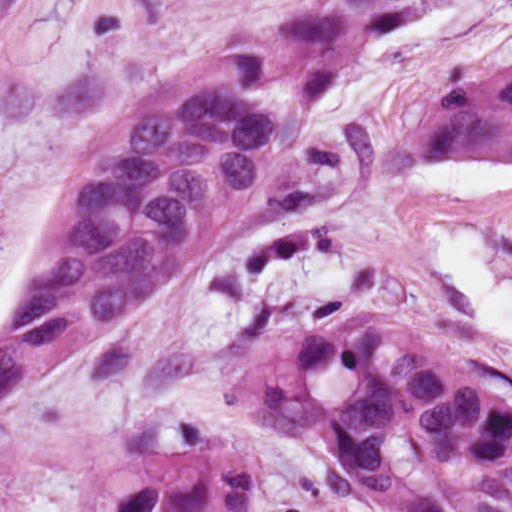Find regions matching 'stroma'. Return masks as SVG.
I'll return each mask as SVG.
<instances>
[{
    "mask_svg": "<svg viewBox=\"0 0 512 512\" xmlns=\"http://www.w3.org/2000/svg\"><path fill=\"white\" fill-rule=\"evenodd\" d=\"M317 1L0 0V269L58 187L60 208L75 154L139 96ZM511 66L512 0H424L318 101L283 80L256 90L305 121L291 153L164 298L33 374L4 416L0 512H74L97 472L168 455L183 422L251 458L249 512H365L318 451L264 432L222 387L260 349L370 317L436 343L512 407V346L449 302L410 144L426 93ZM503 255L512 272V221Z\"/></svg>",
    "mask_w": 512,
    "mask_h": 512,
    "instance_id": "1",
    "label": "stroma"
}]
</instances>
